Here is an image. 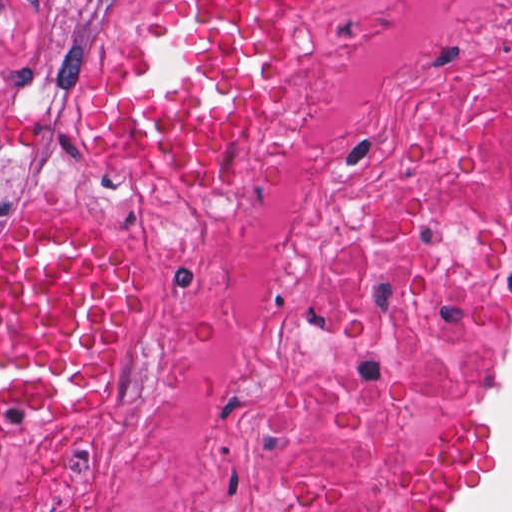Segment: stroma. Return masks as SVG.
<instances>
[{
  "label": "stroma",
  "instance_id": "1",
  "mask_svg": "<svg viewBox=\"0 0 512 512\" xmlns=\"http://www.w3.org/2000/svg\"><path fill=\"white\" fill-rule=\"evenodd\" d=\"M177 1L0 0V237L80 230L117 247L145 276L143 299L100 388L65 418L0 417V461L55 432L144 348L169 317L175 283L220 219L255 113L210 174H157L166 168L113 151L99 136L108 94ZM338 1L306 0L292 9L272 35L269 88L319 42ZM511 359L512 274L437 416L416 512H450L488 474V407Z\"/></svg>",
  "mask_w": 512,
  "mask_h": 512
}]
</instances>
